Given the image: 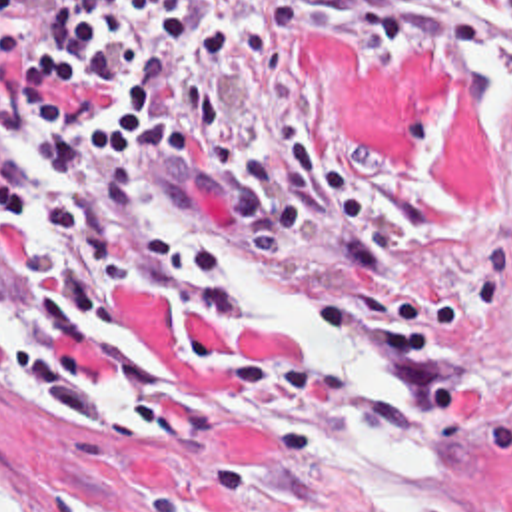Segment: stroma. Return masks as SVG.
<instances>
[{
    "label": "stroma",
    "instance_id": "stroma-1",
    "mask_svg": "<svg viewBox=\"0 0 512 512\" xmlns=\"http://www.w3.org/2000/svg\"><path fill=\"white\" fill-rule=\"evenodd\" d=\"M294 31L310 55L302 99H230V143L260 147L270 115H298L368 191L376 271L340 267L290 239L258 249L232 215V171L182 153L140 187L160 231H186L232 273L334 307L427 369L445 397L443 512H512V75L481 49L414 37ZM16 57H0V95ZM0 173L24 197L58 191L54 169L8 139ZM46 217L0 201V319L22 355L30 253ZM86 361L98 425H76L44 387L0 397V485L10 512H346L322 455L320 413L298 357L228 315L190 313L130 287L96 309Z\"/></svg>",
    "mask_w": 512,
    "mask_h": 512
}]
</instances>
